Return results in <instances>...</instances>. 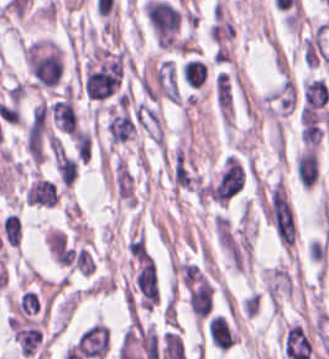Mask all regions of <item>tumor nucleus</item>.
Returning a JSON list of instances; mask_svg holds the SVG:
<instances>
[{
  "instance_id": "2f306a5c",
  "label": "tumor nucleus",
  "mask_w": 329,
  "mask_h": 359,
  "mask_svg": "<svg viewBox=\"0 0 329 359\" xmlns=\"http://www.w3.org/2000/svg\"><path fill=\"white\" fill-rule=\"evenodd\" d=\"M298 100L294 81L286 75L263 97L266 117L278 127L293 112Z\"/></svg>"
}]
</instances>
